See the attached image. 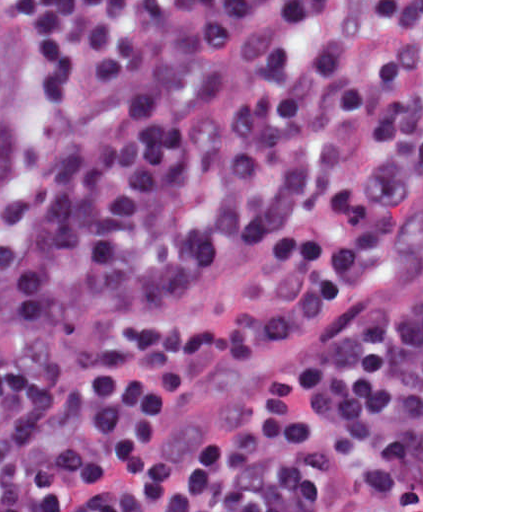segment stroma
<instances>
[{
    "instance_id": "obj_1",
    "label": "stroma",
    "mask_w": 512,
    "mask_h": 512,
    "mask_svg": "<svg viewBox=\"0 0 512 512\" xmlns=\"http://www.w3.org/2000/svg\"><path fill=\"white\" fill-rule=\"evenodd\" d=\"M19 33L15 172L36 115ZM280 305L253 251L198 276L164 317H251ZM294 367V512H423V0H368L348 70L294 133V341L202 357L161 413L153 459L251 426Z\"/></svg>"
}]
</instances>
